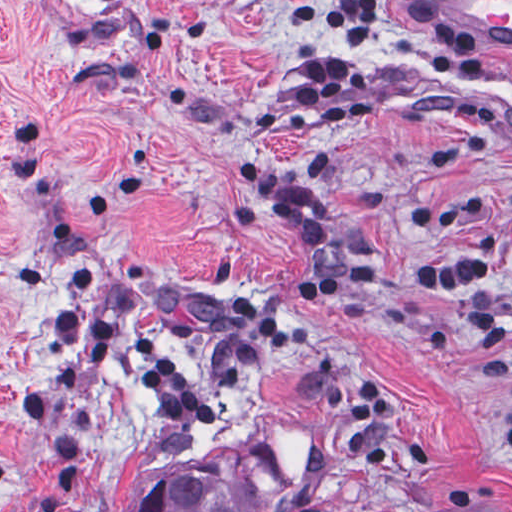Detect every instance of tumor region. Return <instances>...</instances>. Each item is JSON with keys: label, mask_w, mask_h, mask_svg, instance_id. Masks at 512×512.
<instances>
[{"label": "tumor region", "mask_w": 512, "mask_h": 512, "mask_svg": "<svg viewBox=\"0 0 512 512\" xmlns=\"http://www.w3.org/2000/svg\"><path fill=\"white\" fill-rule=\"evenodd\" d=\"M278 491L203 463L151 482L128 512H266Z\"/></svg>", "instance_id": "tumor-region-1"}]
</instances>
